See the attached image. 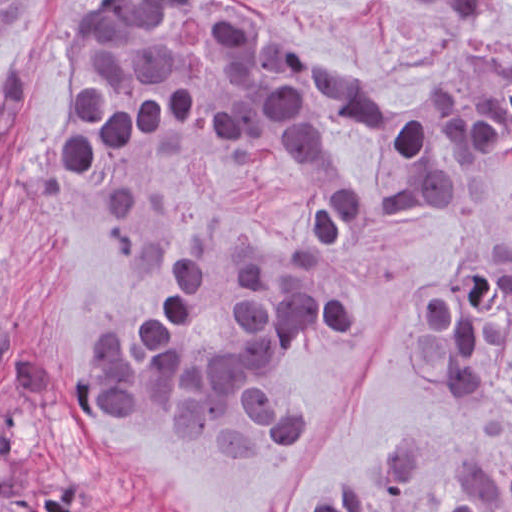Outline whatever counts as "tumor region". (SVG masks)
<instances>
[{
	"label": "tumor region",
	"mask_w": 512,
	"mask_h": 512,
	"mask_svg": "<svg viewBox=\"0 0 512 512\" xmlns=\"http://www.w3.org/2000/svg\"><path fill=\"white\" fill-rule=\"evenodd\" d=\"M37 0H0V36ZM478 10L489 0H414ZM339 132L382 176L341 199L309 237L340 239L377 215L461 220L476 238L506 235L512 202V66L489 76L475 46L422 77L406 98L347 74L323 48L257 0H107L88 12L76 48L68 125L54 160L94 174L161 135L237 162L318 164ZM226 296L235 337L219 353L195 339V255L175 250L171 309L149 329L119 331L91 360L64 364L61 397L78 426L119 422L168 440L270 449L310 432L313 411L286 402L277 371L295 346L343 335L355 310L311 255L230 245ZM408 357L431 385L472 399L509 388L512 241H486L418 304ZM56 364L0 304V494L33 512H103L85 482L38 435ZM301 512H431L425 465L405 455L383 494L332 491ZM443 512H512V460L464 464Z\"/></svg>",
	"instance_id": "e687c5a6"
}]
</instances>
